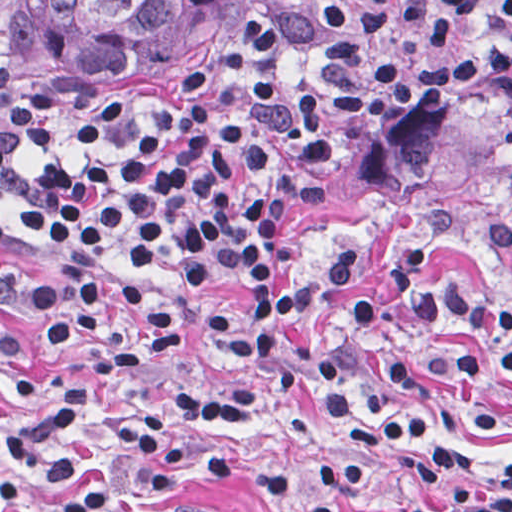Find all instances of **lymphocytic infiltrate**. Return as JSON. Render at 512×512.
<instances>
[{
    "mask_svg": "<svg viewBox=\"0 0 512 512\" xmlns=\"http://www.w3.org/2000/svg\"><path fill=\"white\" fill-rule=\"evenodd\" d=\"M512 95V0H286L272 20L170 117L174 145L143 137L83 106L0 44V109L33 139L72 137L120 146L111 159H64L21 172L0 141V197L36 239L72 264L111 273L76 282L25 283L0 274V362L22 354L40 326L54 370L37 387L14 386L25 420L0 435V493L26 500L35 479L64 492L50 512H105L112 487L86 482L68 444L86 433L113 382L153 374L190 348L181 310L153 279L175 261L178 175L182 222L201 272H247L243 290L207 312L220 352L251 359L255 373L216 388L168 395L179 413L238 422L279 394L320 398L335 458L315 482L348 491L364 452L435 421L386 405L414 383H473L492 369L512 379V300L436 285L429 267L459 228L443 206L387 265L391 293L423 326L452 324L491 345L439 342L391 352L368 396L347 388L348 359L381 320L364 294L346 300L366 246H340L309 275L278 279L279 228L323 203L335 172L387 129L399 107L443 91ZM486 245L512 261V227ZM346 300V301H345ZM313 354L294 362L302 321L343 302ZM444 489L378 512H512V460L458 440L408 465ZM163 512H237L180 496Z\"/></svg>",
    "mask_w": 512,
    "mask_h": 512,
    "instance_id": "f902f5d3",
    "label": "lymphocytic infiltrate"
}]
</instances>
